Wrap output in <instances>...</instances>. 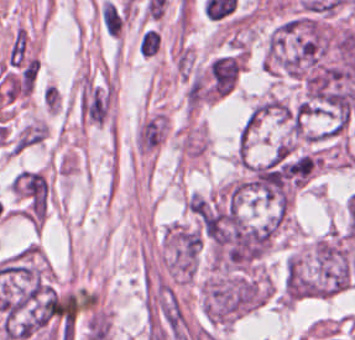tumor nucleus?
<instances>
[{"label": "tumor nucleus", "mask_w": 355, "mask_h": 340, "mask_svg": "<svg viewBox=\"0 0 355 340\" xmlns=\"http://www.w3.org/2000/svg\"><path fill=\"white\" fill-rule=\"evenodd\" d=\"M237 185L246 194L255 199L244 163L242 165Z\"/></svg>", "instance_id": "2f306a5c"}]
</instances>
